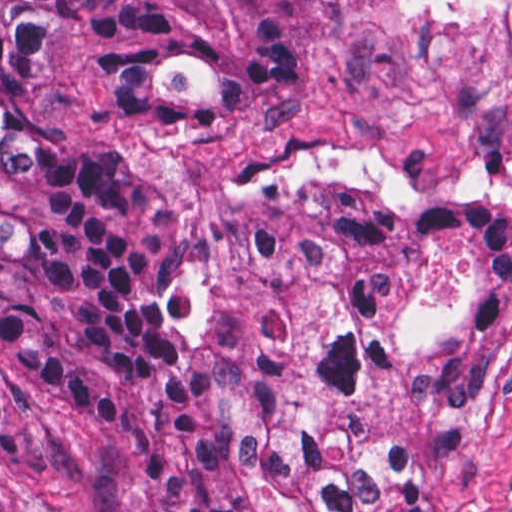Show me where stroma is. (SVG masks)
<instances>
[{"label":"stroma","instance_id":"1","mask_svg":"<svg viewBox=\"0 0 512 512\" xmlns=\"http://www.w3.org/2000/svg\"><path fill=\"white\" fill-rule=\"evenodd\" d=\"M48 122L167 192L194 224L243 195L319 185L401 208L494 200L512 209V0H354L314 86L235 112L115 125L72 47L48 61ZM470 241L439 238L392 318L386 364L335 419L390 440L410 364L452 338L474 305ZM449 512H512V313L436 480ZM0 484L46 512H141L138 465L76 408L0 368Z\"/></svg>","mask_w":512,"mask_h":512}]
</instances>
